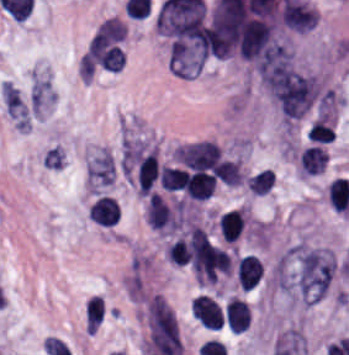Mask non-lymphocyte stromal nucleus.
Returning <instances> with one entry per match:
<instances>
[{
    "mask_svg": "<svg viewBox=\"0 0 349 355\" xmlns=\"http://www.w3.org/2000/svg\"><path fill=\"white\" fill-rule=\"evenodd\" d=\"M64 153L60 146H53L48 149L43 158V165L50 168H60L63 165Z\"/></svg>",
    "mask_w": 349,
    "mask_h": 355,
    "instance_id": "7c5642bf",
    "label": "non-lymphocyte stromal nucleus"
},
{
    "mask_svg": "<svg viewBox=\"0 0 349 355\" xmlns=\"http://www.w3.org/2000/svg\"><path fill=\"white\" fill-rule=\"evenodd\" d=\"M105 313V304L101 295L91 294L84 303L83 322L85 330H97Z\"/></svg>",
    "mask_w": 349,
    "mask_h": 355,
    "instance_id": "3746e769",
    "label": "non-lymphocyte stromal nucleus"
},
{
    "mask_svg": "<svg viewBox=\"0 0 349 355\" xmlns=\"http://www.w3.org/2000/svg\"><path fill=\"white\" fill-rule=\"evenodd\" d=\"M0 96L5 112L16 125L30 126L28 109L15 85L1 82Z\"/></svg>",
    "mask_w": 349,
    "mask_h": 355,
    "instance_id": "dd21d789",
    "label": "non-lymphocyte stromal nucleus"
},
{
    "mask_svg": "<svg viewBox=\"0 0 349 355\" xmlns=\"http://www.w3.org/2000/svg\"><path fill=\"white\" fill-rule=\"evenodd\" d=\"M274 179V172L264 168L249 176L246 182V186L251 194L265 195L272 185Z\"/></svg>",
    "mask_w": 349,
    "mask_h": 355,
    "instance_id": "81446118",
    "label": "non-lymphocyte stromal nucleus"
},
{
    "mask_svg": "<svg viewBox=\"0 0 349 355\" xmlns=\"http://www.w3.org/2000/svg\"><path fill=\"white\" fill-rule=\"evenodd\" d=\"M216 176L222 184L230 186L242 184L243 176L239 161L224 158L216 166Z\"/></svg>",
    "mask_w": 349,
    "mask_h": 355,
    "instance_id": "fc2b8d12",
    "label": "non-lymphocyte stromal nucleus"
},
{
    "mask_svg": "<svg viewBox=\"0 0 349 355\" xmlns=\"http://www.w3.org/2000/svg\"><path fill=\"white\" fill-rule=\"evenodd\" d=\"M112 175V158L107 151L101 148L87 164V183L89 189L95 191L109 184Z\"/></svg>",
    "mask_w": 349,
    "mask_h": 355,
    "instance_id": "a72fc3eb",
    "label": "non-lymphocyte stromal nucleus"
}]
</instances>
